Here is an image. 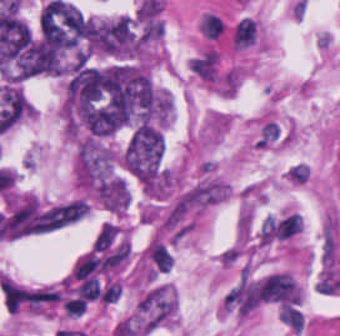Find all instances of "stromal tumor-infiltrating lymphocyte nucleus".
<instances>
[{"instance_id":"stromal-tumor-infiltrating-lymphocyte-nucleus-1","label":"stromal tumor-infiltrating lymphocyte nucleus","mask_w":340,"mask_h":336,"mask_svg":"<svg viewBox=\"0 0 340 336\" xmlns=\"http://www.w3.org/2000/svg\"><path fill=\"white\" fill-rule=\"evenodd\" d=\"M260 297L265 302L291 309L302 301V292L294 277L280 272L260 282Z\"/></svg>"},{"instance_id":"stromal-tumor-infiltrating-lymphocyte-nucleus-2","label":"stromal tumor-infiltrating lymphocyte nucleus","mask_w":340,"mask_h":336,"mask_svg":"<svg viewBox=\"0 0 340 336\" xmlns=\"http://www.w3.org/2000/svg\"><path fill=\"white\" fill-rule=\"evenodd\" d=\"M258 39V25L254 18L242 15L230 24V42L236 50H243Z\"/></svg>"},{"instance_id":"stromal-tumor-infiltrating-lymphocyte-nucleus-3","label":"stromal tumor-infiltrating lymphocyte nucleus","mask_w":340,"mask_h":336,"mask_svg":"<svg viewBox=\"0 0 340 336\" xmlns=\"http://www.w3.org/2000/svg\"><path fill=\"white\" fill-rule=\"evenodd\" d=\"M146 252L160 271L169 272L172 266L171 256L161 242L154 240Z\"/></svg>"}]
</instances>
